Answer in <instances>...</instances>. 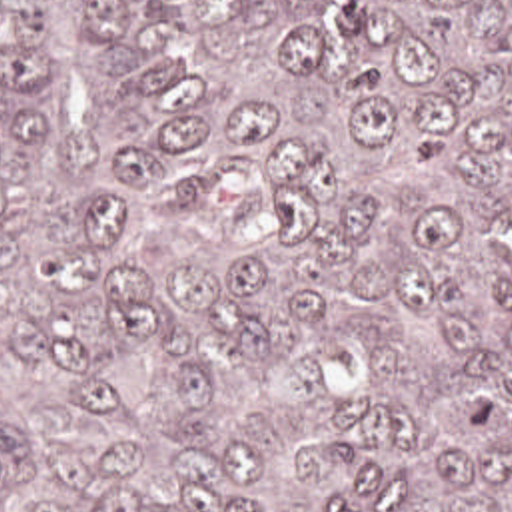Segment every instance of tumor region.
<instances>
[{"instance_id":"tumor-region-1","label":"tumor region","mask_w":512,"mask_h":512,"mask_svg":"<svg viewBox=\"0 0 512 512\" xmlns=\"http://www.w3.org/2000/svg\"><path fill=\"white\" fill-rule=\"evenodd\" d=\"M0 512H512V0H0Z\"/></svg>"}]
</instances>
